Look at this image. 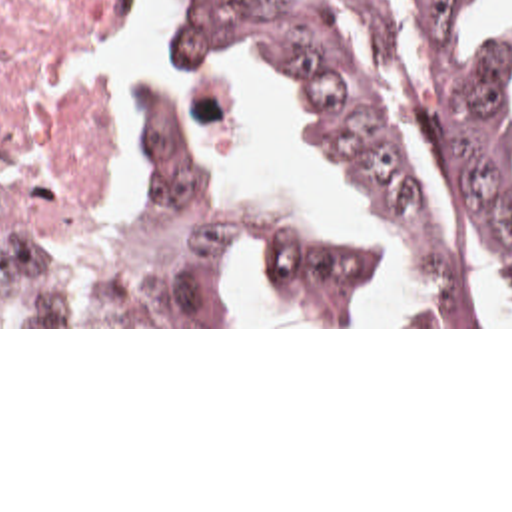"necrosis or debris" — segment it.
Masks as SVG:
<instances>
[{"label":"necrosis or debris","instance_id":"necrosis-or-debris-1","mask_svg":"<svg viewBox=\"0 0 512 512\" xmlns=\"http://www.w3.org/2000/svg\"><path fill=\"white\" fill-rule=\"evenodd\" d=\"M137 0H0V145L111 179L107 83L69 71L75 53L131 26Z\"/></svg>","mask_w":512,"mask_h":512}]
</instances>
